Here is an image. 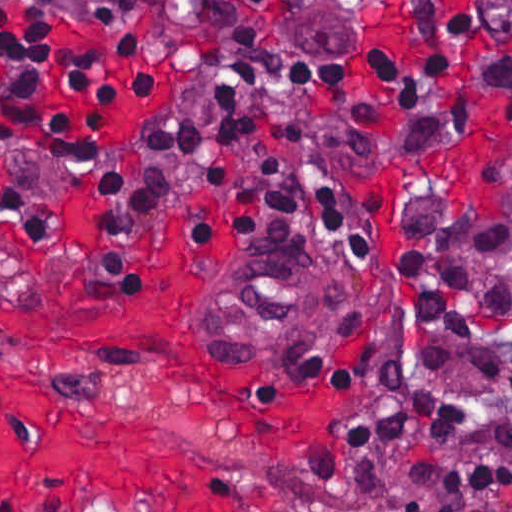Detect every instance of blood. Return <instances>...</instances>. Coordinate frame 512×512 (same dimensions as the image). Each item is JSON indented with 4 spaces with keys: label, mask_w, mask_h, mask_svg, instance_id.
Masks as SVG:
<instances>
[{
    "label": "blood",
    "mask_w": 512,
    "mask_h": 512,
    "mask_svg": "<svg viewBox=\"0 0 512 512\" xmlns=\"http://www.w3.org/2000/svg\"><path fill=\"white\" fill-rule=\"evenodd\" d=\"M167 307L112 304L62 283L0 274V512H49L75 493L107 491L194 512H244V483L220 461L117 423L67 388L10 362L7 331L130 340Z\"/></svg>",
    "instance_id": "1a1defca"
}]
</instances>
